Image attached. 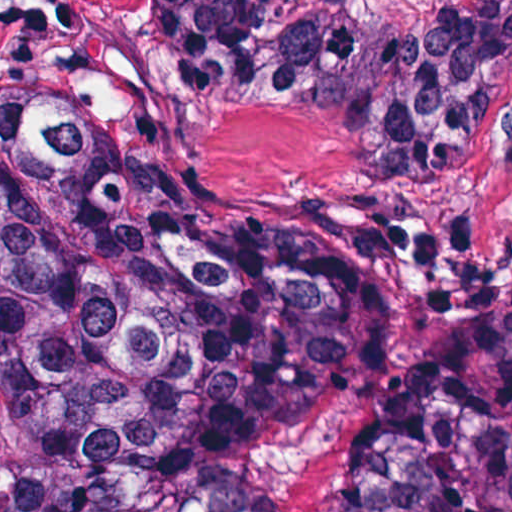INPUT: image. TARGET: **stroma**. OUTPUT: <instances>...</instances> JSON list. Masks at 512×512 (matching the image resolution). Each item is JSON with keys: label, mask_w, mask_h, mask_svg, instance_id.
<instances>
[{"label": "stroma", "mask_w": 512, "mask_h": 512, "mask_svg": "<svg viewBox=\"0 0 512 512\" xmlns=\"http://www.w3.org/2000/svg\"><path fill=\"white\" fill-rule=\"evenodd\" d=\"M440 1L357 3L369 18H418ZM0 77H22L198 210L375 209L414 231L461 234L477 270L512 274V92L474 154L386 164L286 98L182 104L153 0H0Z\"/></svg>", "instance_id": "obj_1"}]
</instances>
